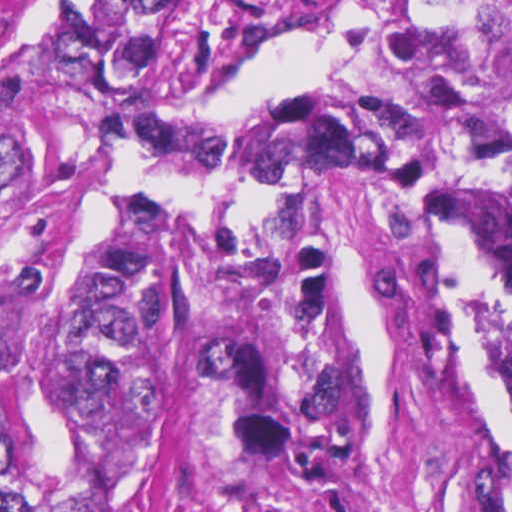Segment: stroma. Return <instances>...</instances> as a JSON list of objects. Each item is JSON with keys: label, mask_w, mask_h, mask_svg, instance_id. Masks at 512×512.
I'll return each instance as SVG.
<instances>
[{"label": "stroma", "mask_w": 512, "mask_h": 512, "mask_svg": "<svg viewBox=\"0 0 512 512\" xmlns=\"http://www.w3.org/2000/svg\"><path fill=\"white\" fill-rule=\"evenodd\" d=\"M368 33L365 0H303L180 112L280 101L352 69ZM169 210L186 276L249 251L298 245L333 261L359 369L352 467L316 479L289 457L237 451L186 366L225 315L182 326L155 393L150 446L118 512H479L449 437V367L464 326L453 254L512 243V216L452 173L415 203L388 207L314 164L280 180L188 182L147 173L107 146L1 160V268L39 267L20 342L68 298L87 246L134 196Z\"/></svg>", "instance_id": "1"}]
</instances>
